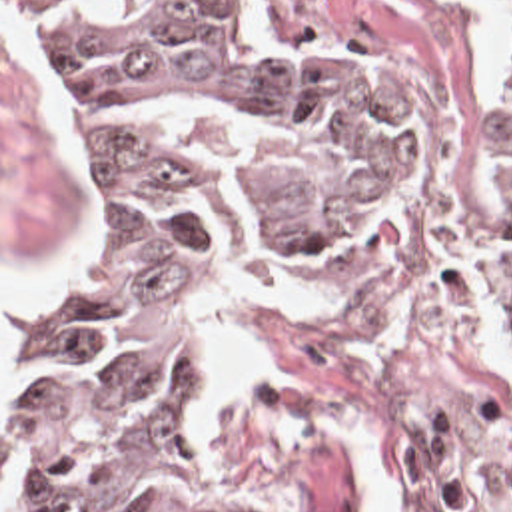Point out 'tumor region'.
<instances>
[{
  "mask_svg": "<svg viewBox=\"0 0 512 512\" xmlns=\"http://www.w3.org/2000/svg\"><path fill=\"white\" fill-rule=\"evenodd\" d=\"M80 143L54 287L2 311V512H238L208 487L184 327L389 213L381 125L268 55L252 0H12ZM512 309V29L499 89Z\"/></svg>",
  "mask_w": 512,
  "mask_h": 512,
  "instance_id": "tumor-region-1",
  "label": "tumor region"
}]
</instances>
